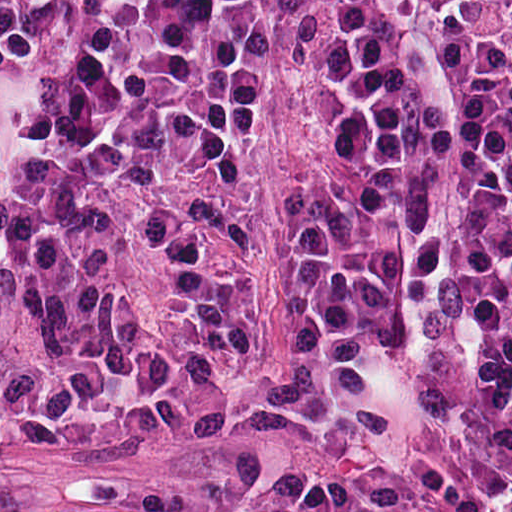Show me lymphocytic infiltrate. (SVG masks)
<instances>
[{"mask_svg": "<svg viewBox=\"0 0 512 512\" xmlns=\"http://www.w3.org/2000/svg\"><path fill=\"white\" fill-rule=\"evenodd\" d=\"M512 362V0H437ZM324 157L294 449L264 512H512V433L375 447L422 243L414 125L367 0H0V411L146 441L191 337L183 179L300 128Z\"/></svg>", "mask_w": 512, "mask_h": 512, "instance_id": "f902f5d3", "label": "lymphocytic infiltrate"}]
</instances>
